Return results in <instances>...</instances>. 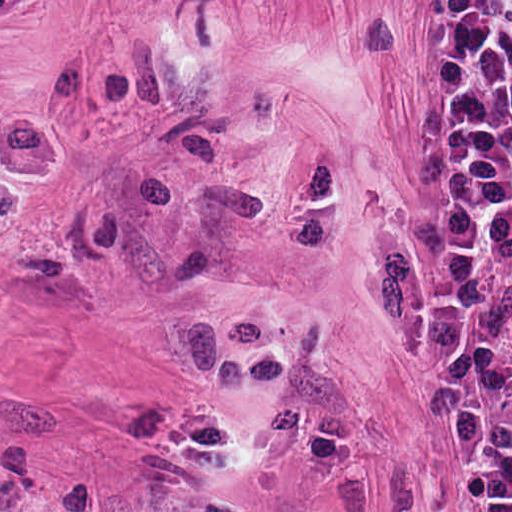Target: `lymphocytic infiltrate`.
Wrapping results in <instances>:
<instances>
[{"label": "lymphocytic infiltrate", "mask_w": 512, "mask_h": 512, "mask_svg": "<svg viewBox=\"0 0 512 512\" xmlns=\"http://www.w3.org/2000/svg\"><path fill=\"white\" fill-rule=\"evenodd\" d=\"M411 328L479 473V512H512V0L423 2Z\"/></svg>", "instance_id": "obj_1"}]
</instances>
